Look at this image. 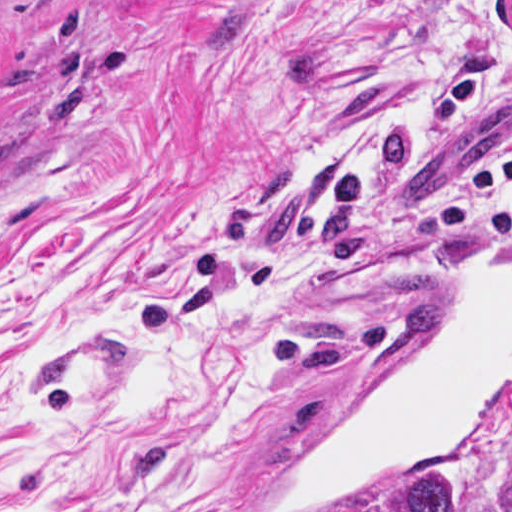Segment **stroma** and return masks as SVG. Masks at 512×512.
<instances>
[{
    "mask_svg": "<svg viewBox=\"0 0 512 512\" xmlns=\"http://www.w3.org/2000/svg\"><path fill=\"white\" fill-rule=\"evenodd\" d=\"M512 66L510 0H0V331L90 322L151 282L257 254L281 376L214 442L178 512H258L309 430L418 319L456 253L396 239L330 195L331 152L457 67ZM512 85L403 160L483 169ZM121 420L74 400L54 464L0 421V512H106ZM439 472L454 512H507L512 398L460 454L352 512H398Z\"/></svg>",
    "mask_w": 512,
    "mask_h": 512,
    "instance_id": "1",
    "label": "stroma"
}]
</instances>
